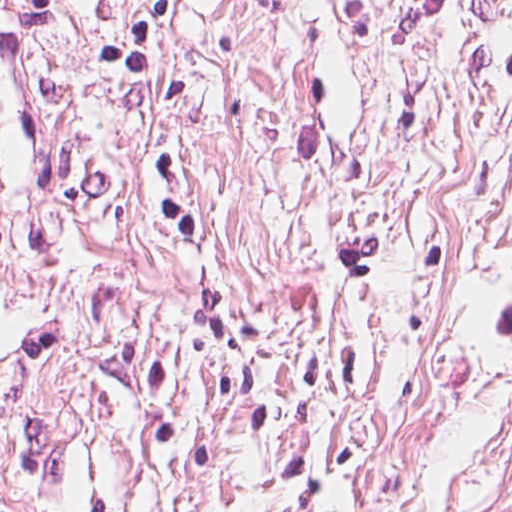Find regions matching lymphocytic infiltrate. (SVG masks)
Masks as SVG:
<instances>
[{"label": "lymphocytic infiltrate", "mask_w": 512, "mask_h": 512, "mask_svg": "<svg viewBox=\"0 0 512 512\" xmlns=\"http://www.w3.org/2000/svg\"><path fill=\"white\" fill-rule=\"evenodd\" d=\"M44 21V0H0V79L35 83V56ZM0 219V252L11 240Z\"/></svg>", "instance_id": "1"}]
</instances>
